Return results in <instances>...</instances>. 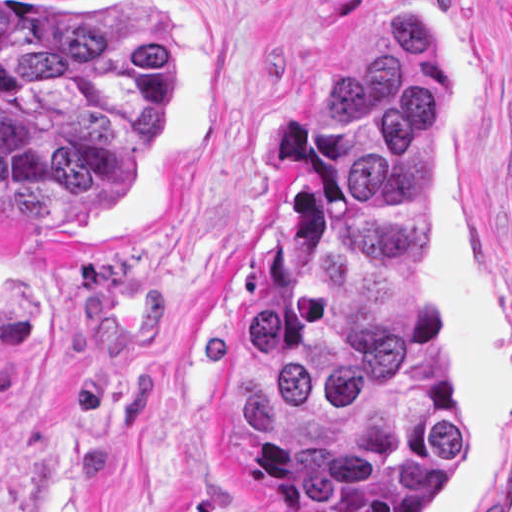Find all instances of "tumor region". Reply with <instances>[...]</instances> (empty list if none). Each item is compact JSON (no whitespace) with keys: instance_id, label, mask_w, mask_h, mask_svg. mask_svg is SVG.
<instances>
[{"instance_id":"e687c5a6","label":"tumor region","mask_w":512,"mask_h":512,"mask_svg":"<svg viewBox=\"0 0 512 512\" xmlns=\"http://www.w3.org/2000/svg\"><path fill=\"white\" fill-rule=\"evenodd\" d=\"M171 43L105 1H0V201L113 209L168 108ZM286 163L258 295L215 356L224 472L296 512H434L464 411L430 327V202L444 86L401 9L325 83Z\"/></svg>"}]
</instances>
